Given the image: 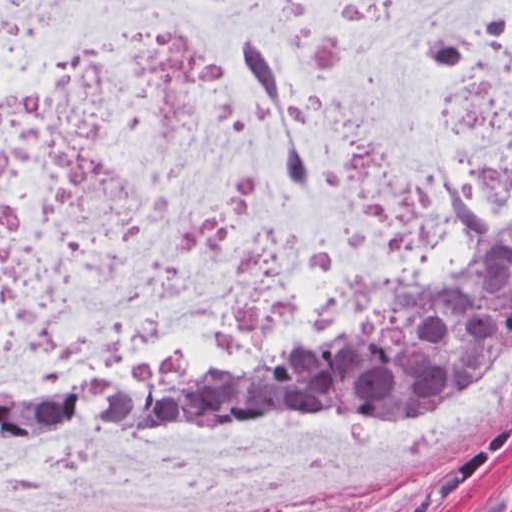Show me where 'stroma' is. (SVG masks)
I'll return each instance as SVG.
<instances>
[{"label":"stroma","mask_w":512,"mask_h":512,"mask_svg":"<svg viewBox=\"0 0 512 512\" xmlns=\"http://www.w3.org/2000/svg\"><path fill=\"white\" fill-rule=\"evenodd\" d=\"M363 318L365 317L340 321L305 333L275 355L313 346ZM494 361L462 382L394 414L368 415L351 409L307 408L287 403H218L188 410L135 432L149 431L164 424L195 418H341L352 421H395L427 410ZM226 366L229 365L174 371H213ZM128 376L133 375L57 387H101ZM321 507H334L335 512H512V411L494 431L456 457L424 465L398 476L371 497L351 500L342 493L333 494L305 512Z\"/></svg>","instance_id":"35a3bbf8"}]
</instances>
